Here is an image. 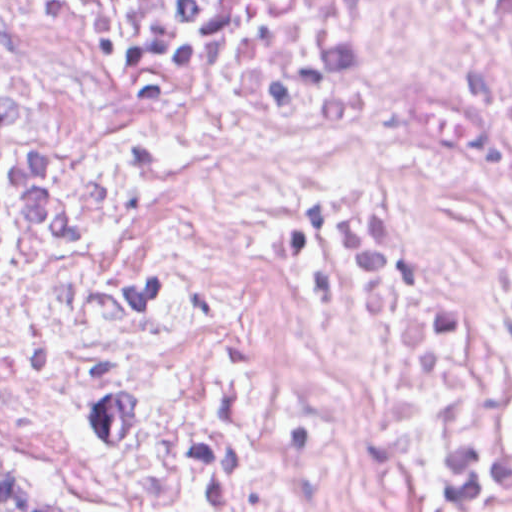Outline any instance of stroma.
I'll return each mask as SVG.
<instances>
[{
    "instance_id": "stroma-1",
    "label": "stroma",
    "mask_w": 512,
    "mask_h": 512,
    "mask_svg": "<svg viewBox=\"0 0 512 512\" xmlns=\"http://www.w3.org/2000/svg\"><path fill=\"white\" fill-rule=\"evenodd\" d=\"M0 469L31 474L53 490L111 512L108 502L65 462L18 444H0Z\"/></svg>"
}]
</instances>
